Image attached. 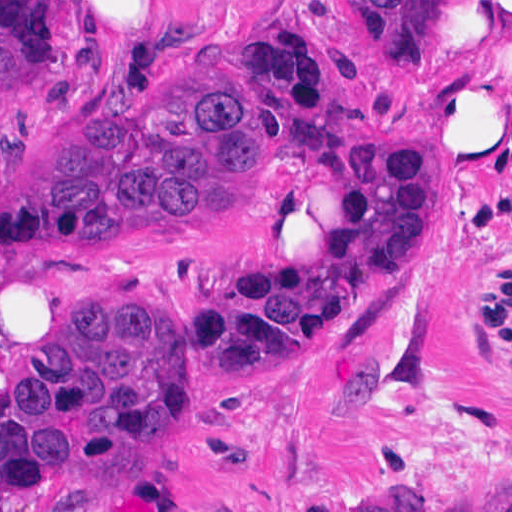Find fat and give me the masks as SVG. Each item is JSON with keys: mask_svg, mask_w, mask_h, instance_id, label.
<instances>
[{"mask_svg": "<svg viewBox=\"0 0 512 512\" xmlns=\"http://www.w3.org/2000/svg\"><path fill=\"white\" fill-rule=\"evenodd\" d=\"M474 35L484 37L483 42L477 57L475 48L439 101L428 164L439 152H478L508 134L512 0H482ZM422 197L458 210L425 182Z\"/></svg>", "mask_w": 512, "mask_h": 512, "instance_id": "53f6f03d", "label": "fat"}]
</instances>
